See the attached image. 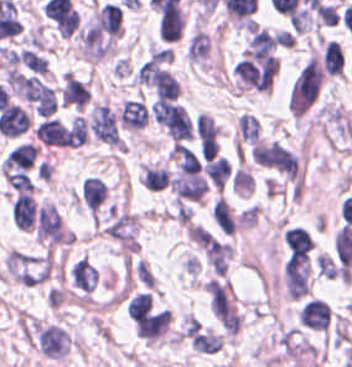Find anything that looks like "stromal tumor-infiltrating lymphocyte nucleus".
Listing matches in <instances>:
<instances>
[{
    "instance_id": "18",
    "label": "stromal tumor-infiltrating lymphocyte nucleus",
    "mask_w": 352,
    "mask_h": 367,
    "mask_svg": "<svg viewBox=\"0 0 352 367\" xmlns=\"http://www.w3.org/2000/svg\"><path fill=\"white\" fill-rule=\"evenodd\" d=\"M195 131L200 154H216L219 129L210 114L199 113Z\"/></svg>"
},
{
    "instance_id": "27",
    "label": "stromal tumor-infiltrating lymphocyte nucleus",
    "mask_w": 352,
    "mask_h": 367,
    "mask_svg": "<svg viewBox=\"0 0 352 367\" xmlns=\"http://www.w3.org/2000/svg\"><path fill=\"white\" fill-rule=\"evenodd\" d=\"M261 137L260 122L253 114L241 113L239 117V140L253 144Z\"/></svg>"
},
{
    "instance_id": "34",
    "label": "stromal tumor-infiltrating lymphocyte nucleus",
    "mask_w": 352,
    "mask_h": 367,
    "mask_svg": "<svg viewBox=\"0 0 352 367\" xmlns=\"http://www.w3.org/2000/svg\"><path fill=\"white\" fill-rule=\"evenodd\" d=\"M18 58L20 62H22L23 64L27 65L28 67L37 72L44 73L47 68L46 58L32 51L29 48H22Z\"/></svg>"
},
{
    "instance_id": "25",
    "label": "stromal tumor-infiltrating lymphocyte nucleus",
    "mask_w": 352,
    "mask_h": 367,
    "mask_svg": "<svg viewBox=\"0 0 352 367\" xmlns=\"http://www.w3.org/2000/svg\"><path fill=\"white\" fill-rule=\"evenodd\" d=\"M344 55L339 44L331 38L324 43L322 66L332 74H340L343 69Z\"/></svg>"
},
{
    "instance_id": "20",
    "label": "stromal tumor-infiltrating lymphocyte nucleus",
    "mask_w": 352,
    "mask_h": 367,
    "mask_svg": "<svg viewBox=\"0 0 352 367\" xmlns=\"http://www.w3.org/2000/svg\"><path fill=\"white\" fill-rule=\"evenodd\" d=\"M298 320L313 328L325 330L330 321V307L319 298L307 300L298 312Z\"/></svg>"
},
{
    "instance_id": "19",
    "label": "stromal tumor-infiltrating lymphocyte nucleus",
    "mask_w": 352,
    "mask_h": 367,
    "mask_svg": "<svg viewBox=\"0 0 352 367\" xmlns=\"http://www.w3.org/2000/svg\"><path fill=\"white\" fill-rule=\"evenodd\" d=\"M69 278L71 286L86 294L95 289L98 281V271L86 258H79L71 263Z\"/></svg>"
},
{
    "instance_id": "32",
    "label": "stromal tumor-infiltrating lymphocyte nucleus",
    "mask_w": 352,
    "mask_h": 367,
    "mask_svg": "<svg viewBox=\"0 0 352 367\" xmlns=\"http://www.w3.org/2000/svg\"><path fill=\"white\" fill-rule=\"evenodd\" d=\"M88 139L86 119L75 115L68 130L66 142L71 145H78Z\"/></svg>"
},
{
    "instance_id": "17",
    "label": "stromal tumor-infiltrating lymphocyte nucleus",
    "mask_w": 352,
    "mask_h": 367,
    "mask_svg": "<svg viewBox=\"0 0 352 367\" xmlns=\"http://www.w3.org/2000/svg\"><path fill=\"white\" fill-rule=\"evenodd\" d=\"M137 332L142 337L154 338L166 328L170 319V310L158 309L132 316Z\"/></svg>"
},
{
    "instance_id": "2",
    "label": "stromal tumor-infiltrating lymphocyte nucleus",
    "mask_w": 352,
    "mask_h": 367,
    "mask_svg": "<svg viewBox=\"0 0 352 367\" xmlns=\"http://www.w3.org/2000/svg\"><path fill=\"white\" fill-rule=\"evenodd\" d=\"M2 176L11 188H26L47 178V160L34 141L17 139L2 156Z\"/></svg>"
},
{
    "instance_id": "8",
    "label": "stromal tumor-infiltrating lymphocyte nucleus",
    "mask_w": 352,
    "mask_h": 367,
    "mask_svg": "<svg viewBox=\"0 0 352 367\" xmlns=\"http://www.w3.org/2000/svg\"><path fill=\"white\" fill-rule=\"evenodd\" d=\"M34 342L48 357H62L69 351L70 336L56 321L34 324Z\"/></svg>"
},
{
    "instance_id": "37",
    "label": "stromal tumor-infiltrating lymphocyte nucleus",
    "mask_w": 352,
    "mask_h": 367,
    "mask_svg": "<svg viewBox=\"0 0 352 367\" xmlns=\"http://www.w3.org/2000/svg\"><path fill=\"white\" fill-rule=\"evenodd\" d=\"M156 98L175 99L178 95V82L174 79H163L155 88Z\"/></svg>"
},
{
    "instance_id": "4",
    "label": "stromal tumor-infiltrating lymphocyte nucleus",
    "mask_w": 352,
    "mask_h": 367,
    "mask_svg": "<svg viewBox=\"0 0 352 367\" xmlns=\"http://www.w3.org/2000/svg\"><path fill=\"white\" fill-rule=\"evenodd\" d=\"M9 83L37 113L50 114L55 108V91L34 74L12 72Z\"/></svg>"
},
{
    "instance_id": "9",
    "label": "stromal tumor-infiltrating lymphocyte nucleus",
    "mask_w": 352,
    "mask_h": 367,
    "mask_svg": "<svg viewBox=\"0 0 352 367\" xmlns=\"http://www.w3.org/2000/svg\"><path fill=\"white\" fill-rule=\"evenodd\" d=\"M151 108L159 123L173 139L188 130L190 118L183 105L165 98H156Z\"/></svg>"
},
{
    "instance_id": "7",
    "label": "stromal tumor-infiltrating lymphocyte nucleus",
    "mask_w": 352,
    "mask_h": 367,
    "mask_svg": "<svg viewBox=\"0 0 352 367\" xmlns=\"http://www.w3.org/2000/svg\"><path fill=\"white\" fill-rule=\"evenodd\" d=\"M136 78L161 89L173 83V52L169 48H156L141 63Z\"/></svg>"
},
{
    "instance_id": "1",
    "label": "stromal tumor-infiltrating lymphocyte nucleus",
    "mask_w": 352,
    "mask_h": 367,
    "mask_svg": "<svg viewBox=\"0 0 352 367\" xmlns=\"http://www.w3.org/2000/svg\"><path fill=\"white\" fill-rule=\"evenodd\" d=\"M122 28V5L116 1H102L80 29L84 56L106 58L114 53Z\"/></svg>"
},
{
    "instance_id": "13",
    "label": "stromal tumor-infiltrating lymphocyte nucleus",
    "mask_w": 352,
    "mask_h": 367,
    "mask_svg": "<svg viewBox=\"0 0 352 367\" xmlns=\"http://www.w3.org/2000/svg\"><path fill=\"white\" fill-rule=\"evenodd\" d=\"M149 115V105L142 98H128L120 107L116 120L120 129L138 130L145 125Z\"/></svg>"
},
{
    "instance_id": "21",
    "label": "stromal tumor-infiltrating lymphocyte nucleus",
    "mask_w": 352,
    "mask_h": 367,
    "mask_svg": "<svg viewBox=\"0 0 352 367\" xmlns=\"http://www.w3.org/2000/svg\"><path fill=\"white\" fill-rule=\"evenodd\" d=\"M89 95L90 92L85 84L72 74H65L61 90V101L64 104L82 109Z\"/></svg>"
},
{
    "instance_id": "33",
    "label": "stromal tumor-infiltrating lymphocyte nucleus",
    "mask_w": 352,
    "mask_h": 367,
    "mask_svg": "<svg viewBox=\"0 0 352 367\" xmlns=\"http://www.w3.org/2000/svg\"><path fill=\"white\" fill-rule=\"evenodd\" d=\"M152 307V298L147 291H139L127 304L128 315L132 318L147 311Z\"/></svg>"
},
{
    "instance_id": "30",
    "label": "stromal tumor-infiltrating lymphocyte nucleus",
    "mask_w": 352,
    "mask_h": 367,
    "mask_svg": "<svg viewBox=\"0 0 352 367\" xmlns=\"http://www.w3.org/2000/svg\"><path fill=\"white\" fill-rule=\"evenodd\" d=\"M174 152L179 171H199L200 161L190 146L179 143L176 145Z\"/></svg>"
},
{
    "instance_id": "28",
    "label": "stromal tumor-infiltrating lymphocyte nucleus",
    "mask_w": 352,
    "mask_h": 367,
    "mask_svg": "<svg viewBox=\"0 0 352 367\" xmlns=\"http://www.w3.org/2000/svg\"><path fill=\"white\" fill-rule=\"evenodd\" d=\"M170 176L165 166H142V181L144 187L160 189L168 185Z\"/></svg>"
},
{
    "instance_id": "15",
    "label": "stromal tumor-infiltrating lymphocyte nucleus",
    "mask_w": 352,
    "mask_h": 367,
    "mask_svg": "<svg viewBox=\"0 0 352 367\" xmlns=\"http://www.w3.org/2000/svg\"><path fill=\"white\" fill-rule=\"evenodd\" d=\"M203 253L212 272L225 275L232 255L230 242L210 234Z\"/></svg>"
},
{
    "instance_id": "3",
    "label": "stromal tumor-infiltrating lymphocyte nucleus",
    "mask_w": 352,
    "mask_h": 367,
    "mask_svg": "<svg viewBox=\"0 0 352 367\" xmlns=\"http://www.w3.org/2000/svg\"><path fill=\"white\" fill-rule=\"evenodd\" d=\"M6 266L15 280L40 284L47 280L52 269V254L12 249L6 258Z\"/></svg>"
},
{
    "instance_id": "10",
    "label": "stromal tumor-infiltrating lymphocyte nucleus",
    "mask_w": 352,
    "mask_h": 367,
    "mask_svg": "<svg viewBox=\"0 0 352 367\" xmlns=\"http://www.w3.org/2000/svg\"><path fill=\"white\" fill-rule=\"evenodd\" d=\"M252 157L280 171L293 172L292 151L273 140H257L252 145Z\"/></svg>"
},
{
    "instance_id": "29",
    "label": "stromal tumor-infiltrating lymphocyte nucleus",
    "mask_w": 352,
    "mask_h": 367,
    "mask_svg": "<svg viewBox=\"0 0 352 367\" xmlns=\"http://www.w3.org/2000/svg\"><path fill=\"white\" fill-rule=\"evenodd\" d=\"M190 339L193 346L201 352H215L220 347L222 337L208 327L190 336Z\"/></svg>"
},
{
    "instance_id": "5",
    "label": "stromal tumor-infiltrating lymphocyte nucleus",
    "mask_w": 352,
    "mask_h": 367,
    "mask_svg": "<svg viewBox=\"0 0 352 367\" xmlns=\"http://www.w3.org/2000/svg\"><path fill=\"white\" fill-rule=\"evenodd\" d=\"M322 79V68L312 56L295 78L290 97L291 113H304L316 98Z\"/></svg>"
},
{
    "instance_id": "22",
    "label": "stromal tumor-infiltrating lymphocyte nucleus",
    "mask_w": 352,
    "mask_h": 367,
    "mask_svg": "<svg viewBox=\"0 0 352 367\" xmlns=\"http://www.w3.org/2000/svg\"><path fill=\"white\" fill-rule=\"evenodd\" d=\"M35 135L43 140L46 144H66L67 145V131L66 126L57 119L48 118L42 119L35 131Z\"/></svg>"
},
{
    "instance_id": "16",
    "label": "stromal tumor-infiltrating lymphocyte nucleus",
    "mask_w": 352,
    "mask_h": 367,
    "mask_svg": "<svg viewBox=\"0 0 352 367\" xmlns=\"http://www.w3.org/2000/svg\"><path fill=\"white\" fill-rule=\"evenodd\" d=\"M107 196L106 181L95 175H87L80 192L85 207L97 218Z\"/></svg>"
},
{
    "instance_id": "36",
    "label": "stromal tumor-infiltrating lymphocyte nucleus",
    "mask_w": 352,
    "mask_h": 367,
    "mask_svg": "<svg viewBox=\"0 0 352 367\" xmlns=\"http://www.w3.org/2000/svg\"><path fill=\"white\" fill-rule=\"evenodd\" d=\"M317 270L324 276L336 277L340 274V267L330 255L318 253L314 258Z\"/></svg>"
},
{
    "instance_id": "23",
    "label": "stromal tumor-infiltrating lymphocyte nucleus",
    "mask_w": 352,
    "mask_h": 367,
    "mask_svg": "<svg viewBox=\"0 0 352 367\" xmlns=\"http://www.w3.org/2000/svg\"><path fill=\"white\" fill-rule=\"evenodd\" d=\"M210 39L201 28L194 30L188 38L185 54L193 62H201L208 54Z\"/></svg>"
},
{
    "instance_id": "26",
    "label": "stromal tumor-infiltrating lymphocyte nucleus",
    "mask_w": 352,
    "mask_h": 367,
    "mask_svg": "<svg viewBox=\"0 0 352 367\" xmlns=\"http://www.w3.org/2000/svg\"><path fill=\"white\" fill-rule=\"evenodd\" d=\"M230 172V161L221 155L211 157L205 167V173L208 179L220 189L224 186Z\"/></svg>"
},
{
    "instance_id": "12",
    "label": "stromal tumor-infiltrating lymphocyte nucleus",
    "mask_w": 352,
    "mask_h": 367,
    "mask_svg": "<svg viewBox=\"0 0 352 367\" xmlns=\"http://www.w3.org/2000/svg\"><path fill=\"white\" fill-rule=\"evenodd\" d=\"M210 311L232 312L233 297L230 281L220 274H213L205 285Z\"/></svg>"
},
{
    "instance_id": "6",
    "label": "stromal tumor-infiltrating lymphocyte nucleus",
    "mask_w": 352,
    "mask_h": 367,
    "mask_svg": "<svg viewBox=\"0 0 352 367\" xmlns=\"http://www.w3.org/2000/svg\"><path fill=\"white\" fill-rule=\"evenodd\" d=\"M276 66L277 61L271 53L245 50L237 63L236 74L257 88L269 90Z\"/></svg>"
},
{
    "instance_id": "14",
    "label": "stromal tumor-infiltrating lymphocyte nucleus",
    "mask_w": 352,
    "mask_h": 367,
    "mask_svg": "<svg viewBox=\"0 0 352 367\" xmlns=\"http://www.w3.org/2000/svg\"><path fill=\"white\" fill-rule=\"evenodd\" d=\"M177 201H196L207 189L206 179L198 171H184L172 177Z\"/></svg>"
},
{
    "instance_id": "35",
    "label": "stromal tumor-infiltrating lymphocyte nucleus",
    "mask_w": 352,
    "mask_h": 367,
    "mask_svg": "<svg viewBox=\"0 0 352 367\" xmlns=\"http://www.w3.org/2000/svg\"><path fill=\"white\" fill-rule=\"evenodd\" d=\"M39 239L50 242H61L64 239V230L60 215L56 211Z\"/></svg>"
},
{
    "instance_id": "38",
    "label": "stromal tumor-infiltrating lymphocyte nucleus",
    "mask_w": 352,
    "mask_h": 367,
    "mask_svg": "<svg viewBox=\"0 0 352 367\" xmlns=\"http://www.w3.org/2000/svg\"><path fill=\"white\" fill-rule=\"evenodd\" d=\"M217 318L220 320V322L223 324V326L228 331H236V329L239 327L241 319L235 310L215 314Z\"/></svg>"
},
{
    "instance_id": "31",
    "label": "stromal tumor-infiltrating lymphocyte nucleus",
    "mask_w": 352,
    "mask_h": 367,
    "mask_svg": "<svg viewBox=\"0 0 352 367\" xmlns=\"http://www.w3.org/2000/svg\"><path fill=\"white\" fill-rule=\"evenodd\" d=\"M213 217L224 233H232L235 230L229 203L221 196L214 206Z\"/></svg>"
},
{
    "instance_id": "24",
    "label": "stromal tumor-infiltrating lymphocyte nucleus",
    "mask_w": 352,
    "mask_h": 367,
    "mask_svg": "<svg viewBox=\"0 0 352 367\" xmlns=\"http://www.w3.org/2000/svg\"><path fill=\"white\" fill-rule=\"evenodd\" d=\"M283 236L292 254L302 256L313 246V241L310 235L300 227H287Z\"/></svg>"
},
{
    "instance_id": "11",
    "label": "stromal tumor-infiltrating lymphocyte nucleus",
    "mask_w": 352,
    "mask_h": 367,
    "mask_svg": "<svg viewBox=\"0 0 352 367\" xmlns=\"http://www.w3.org/2000/svg\"><path fill=\"white\" fill-rule=\"evenodd\" d=\"M287 292L291 296H300L308 290L309 263L308 257L291 254L284 267Z\"/></svg>"
}]
</instances>
